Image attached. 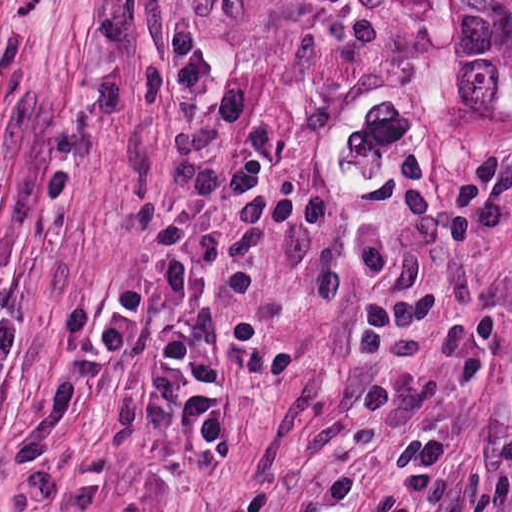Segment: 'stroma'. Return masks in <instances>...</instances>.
I'll list each match as a JSON object with an SVG mask.
<instances>
[{"label": "stroma", "instance_id": "35a3bbf8", "mask_svg": "<svg viewBox=\"0 0 512 512\" xmlns=\"http://www.w3.org/2000/svg\"><path fill=\"white\" fill-rule=\"evenodd\" d=\"M484 310L508 321L502 352L434 413L454 450V512H512V79L429 334Z\"/></svg>", "mask_w": 512, "mask_h": 512}]
</instances>
